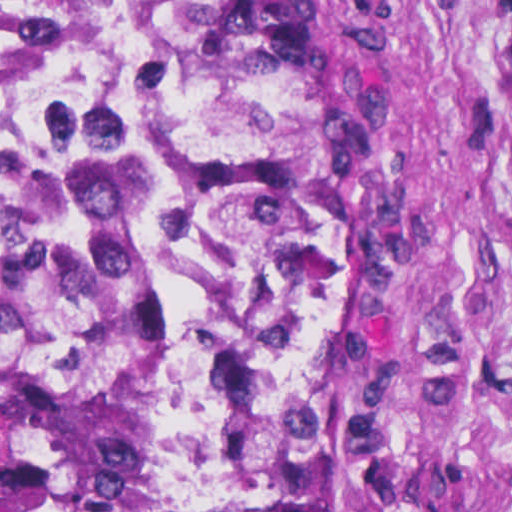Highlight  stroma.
<instances>
[{"mask_svg": "<svg viewBox=\"0 0 512 512\" xmlns=\"http://www.w3.org/2000/svg\"><path fill=\"white\" fill-rule=\"evenodd\" d=\"M378 265L386 512H512V0H301Z\"/></svg>", "mask_w": 512, "mask_h": 512, "instance_id": "stroma-1", "label": "stroma"}]
</instances>
